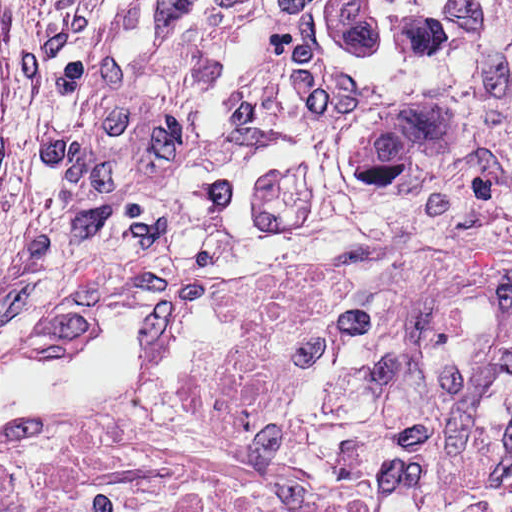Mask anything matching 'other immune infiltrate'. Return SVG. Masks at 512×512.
<instances>
[{"instance_id": "1", "label": "other immune infiltrate", "mask_w": 512, "mask_h": 512, "mask_svg": "<svg viewBox=\"0 0 512 512\" xmlns=\"http://www.w3.org/2000/svg\"><path fill=\"white\" fill-rule=\"evenodd\" d=\"M94 212L234 232L421 231L512 214V0H242L133 48L86 128ZM186 463L110 427L0 447V502L162 490Z\"/></svg>"}]
</instances>
